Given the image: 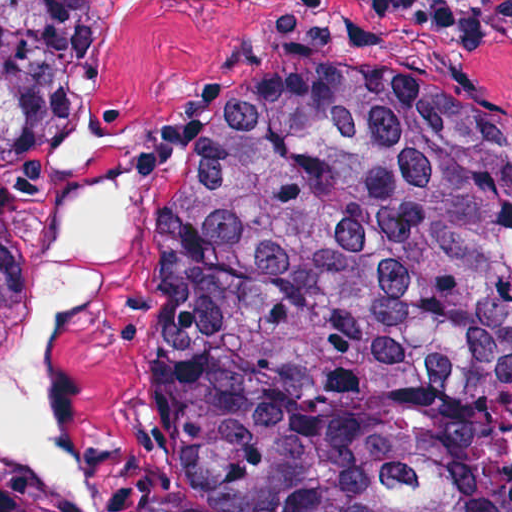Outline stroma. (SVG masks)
Returning a JSON list of instances; mask_svg holds the SVG:
<instances>
[{
	"mask_svg": "<svg viewBox=\"0 0 512 512\" xmlns=\"http://www.w3.org/2000/svg\"><path fill=\"white\" fill-rule=\"evenodd\" d=\"M353 76L418 83L512 132V0H203L117 61L104 116L143 151V185L122 256L78 316L66 370L69 431L101 491L92 506L81 504L0 454L2 483L52 512H158L152 382L163 295L148 224L171 173L178 111L204 91ZM64 140L65 123L59 162ZM42 207L19 226L28 286L10 335L37 302Z\"/></svg>",
	"mask_w": 512,
	"mask_h": 512,
	"instance_id": "stroma-1",
	"label": "stroma"
}]
</instances>
